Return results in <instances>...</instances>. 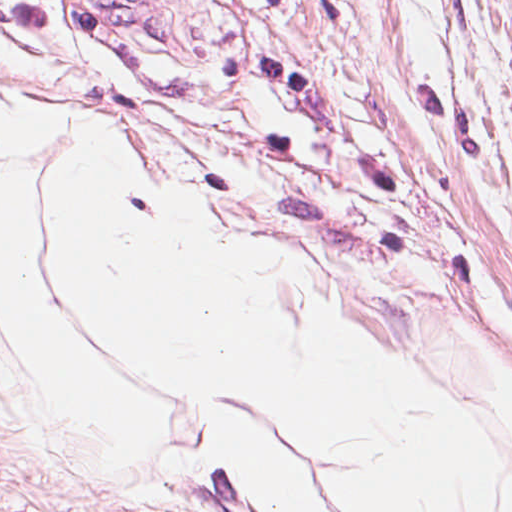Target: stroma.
<instances>
[{"label": "stroma", "mask_w": 512, "mask_h": 512, "mask_svg": "<svg viewBox=\"0 0 512 512\" xmlns=\"http://www.w3.org/2000/svg\"><path fill=\"white\" fill-rule=\"evenodd\" d=\"M0 53L512 161V0H0Z\"/></svg>", "instance_id": "35a3bbf8"}]
</instances>
